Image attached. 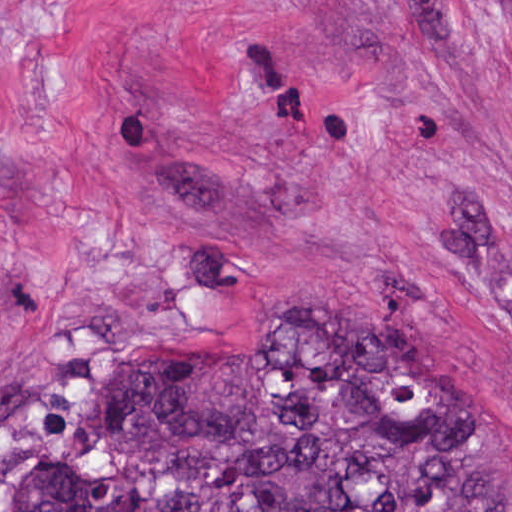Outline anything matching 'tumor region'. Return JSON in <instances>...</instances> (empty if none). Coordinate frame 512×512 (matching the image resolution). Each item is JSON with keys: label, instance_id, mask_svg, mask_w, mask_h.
<instances>
[{"label": "tumor region", "instance_id": "obj_1", "mask_svg": "<svg viewBox=\"0 0 512 512\" xmlns=\"http://www.w3.org/2000/svg\"><path fill=\"white\" fill-rule=\"evenodd\" d=\"M0 512H512V452L364 315L279 346L146 334L71 368Z\"/></svg>", "mask_w": 512, "mask_h": 512}]
</instances>
